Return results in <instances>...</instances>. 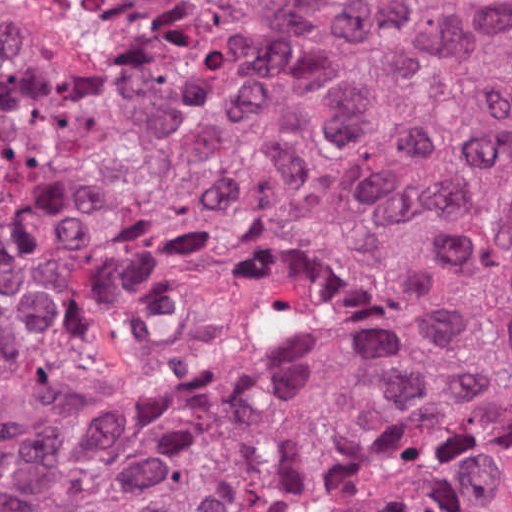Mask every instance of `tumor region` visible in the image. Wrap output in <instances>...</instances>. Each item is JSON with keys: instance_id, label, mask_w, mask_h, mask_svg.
Wrapping results in <instances>:
<instances>
[{"instance_id": "e687c5a6", "label": "tumor region", "mask_w": 512, "mask_h": 512, "mask_svg": "<svg viewBox=\"0 0 512 512\" xmlns=\"http://www.w3.org/2000/svg\"><path fill=\"white\" fill-rule=\"evenodd\" d=\"M0 32V512H512V1H127Z\"/></svg>"}]
</instances>
